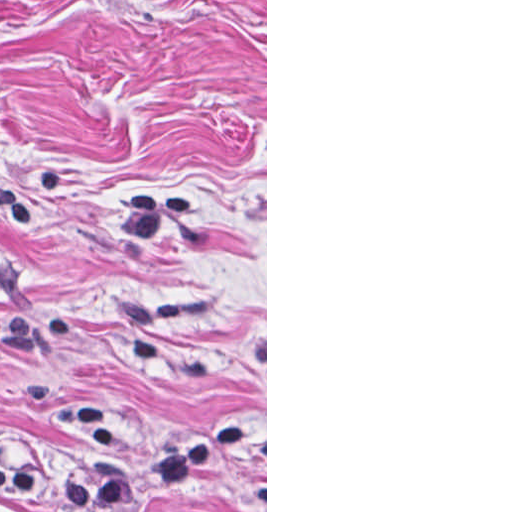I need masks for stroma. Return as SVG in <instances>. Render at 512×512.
Listing matches in <instances>:
<instances>
[{"label":"stroma","mask_w":512,"mask_h":512,"mask_svg":"<svg viewBox=\"0 0 512 512\" xmlns=\"http://www.w3.org/2000/svg\"><path fill=\"white\" fill-rule=\"evenodd\" d=\"M258 438L136 507L267 512V0H0V466Z\"/></svg>","instance_id":"obj_1"}]
</instances>
